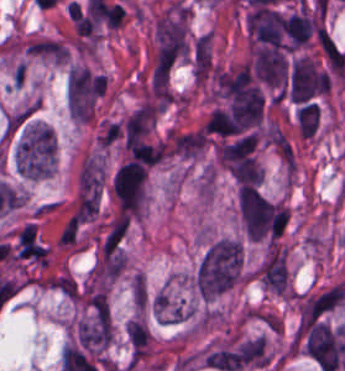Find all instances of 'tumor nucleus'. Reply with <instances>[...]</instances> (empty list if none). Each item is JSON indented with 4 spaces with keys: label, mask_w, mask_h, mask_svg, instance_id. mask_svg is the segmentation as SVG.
Wrapping results in <instances>:
<instances>
[{
    "label": "tumor nucleus",
    "mask_w": 345,
    "mask_h": 371,
    "mask_svg": "<svg viewBox=\"0 0 345 371\" xmlns=\"http://www.w3.org/2000/svg\"><path fill=\"white\" fill-rule=\"evenodd\" d=\"M242 271L240 239L221 237L209 244L196 267V288L202 298L211 299L236 285Z\"/></svg>",
    "instance_id": "2f306a5c"
},
{
    "label": "tumor nucleus",
    "mask_w": 345,
    "mask_h": 371,
    "mask_svg": "<svg viewBox=\"0 0 345 371\" xmlns=\"http://www.w3.org/2000/svg\"><path fill=\"white\" fill-rule=\"evenodd\" d=\"M16 169L28 178L50 175L56 165V141L50 125L29 119L23 126L16 153Z\"/></svg>",
    "instance_id": "8643909e"
},
{
    "label": "tumor nucleus",
    "mask_w": 345,
    "mask_h": 371,
    "mask_svg": "<svg viewBox=\"0 0 345 371\" xmlns=\"http://www.w3.org/2000/svg\"><path fill=\"white\" fill-rule=\"evenodd\" d=\"M263 112L264 102L254 84L232 94L230 115L238 134L260 125Z\"/></svg>",
    "instance_id": "5ab6c2c4"
},
{
    "label": "tumor nucleus",
    "mask_w": 345,
    "mask_h": 371,
    "mask_svg": "<svg viewBox=\"0 0 345 371\" xmlns=\"http://www.w3.org/2000/svg\"><path fill=\"white\" fill-rule=\"evenodd\" d=\"M320 108L318 103L308 102L295 112L299 131L303 136L310 137L318 127Z\"/></svg>",
    "instance_id": "2cbd58db"
},
{
    "label": "tumor nucleus",
    "mask_w": 345,
    "mask_h": 371,
    "mask_svg": "<svg viewBox=\"0 0 345 371\" xmlns=\"http://www.w3.org/2000/svg\"><path fill=\"white\" fill-rule=\"evenodd\" d=\"M126 333L134 350H138L146 343L149 334L145 323L139 320H130L126 323Z\"/></svg>",
    "instance_id": "3d1891a8"
}]
</instances>
